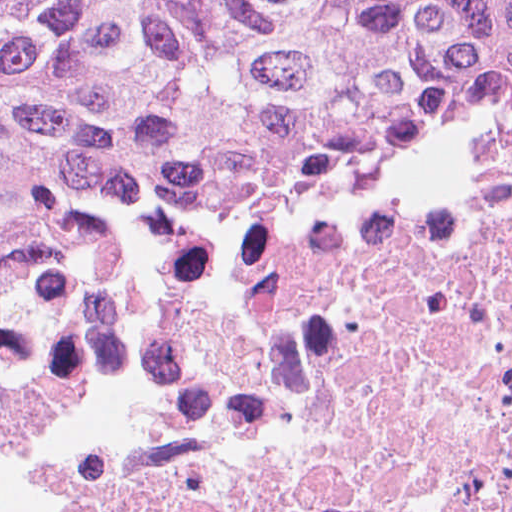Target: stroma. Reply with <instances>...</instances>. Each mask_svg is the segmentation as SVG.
Instances as JSON below:
<instances>
[{"instance_id": "obj_1", "label": "stroma", "mask_w": 512, "mask_h": 512, "mask_svg": "<svg viewBox=\"0 0 512 512\" xmlns=\"http://www.w3.org/2000/svg\"><path fill=\"white\" fill-rule=\"evenodd\" d=\"M511 132L512 92L459 124L349 175H445L486 155ZM265 193L270 192L174 196L132 180L105 176L85 196L74 217L93 212H159Z\"/></svg>"}]
</instances>
